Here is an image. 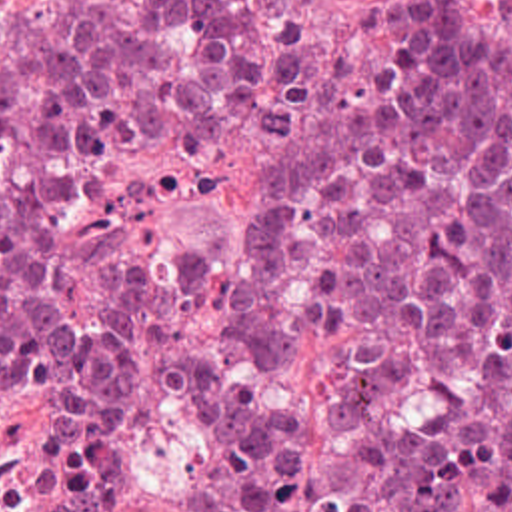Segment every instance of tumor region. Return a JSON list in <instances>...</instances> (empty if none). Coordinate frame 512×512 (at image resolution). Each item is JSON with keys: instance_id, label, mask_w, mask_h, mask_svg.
Wrapping results in <instances>:
<instances>
[{"instance_id": "tumor-region-1", "label": "tumor region", "mask_w": 512, "mask_h": 512, "mask_svg": "<svg viewBox=\"0 0 512 512\" xmlns=\"http://www.w3.org/2000/svg\"><path fill=\"white\" fill-rule=\"evenodd\" d=\"M251 107L249 271L155 243L97 315L57 193H0V347L67 401L69 512H512V37L387 0L377 57L311 0H0V135L175 151Z\"/></svg>"}]
</instances>
